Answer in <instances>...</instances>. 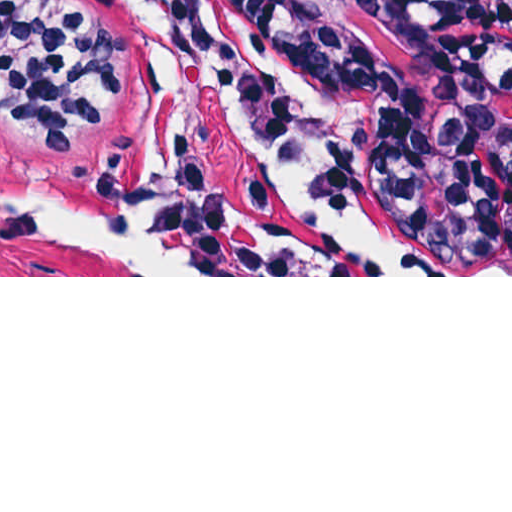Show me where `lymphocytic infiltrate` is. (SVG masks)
Returning <instances> with one entry per match:
<instances>
[{
	"mask_svg": "<svg viewBox=\"0 0 512 512\" xmlns=\"http://www.w3.org/2000/svg\"><path fill=\"white\" fill-rule=\"evenodd\" d=\"M512 63L507 0H408ZM120 87L117 39L69 0H0V123L69 157L108 118Z\"/></svg>",
	"mask_w": 512,
	"mask_h": 512,
	"instance_id": "lymphocytic-infiltrate-1",
	"label": "lymphocytic infiltrate"
}]
</instances>
